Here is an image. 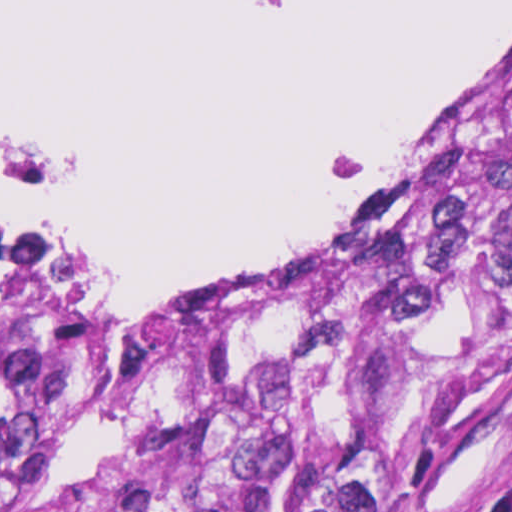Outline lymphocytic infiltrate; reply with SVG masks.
<instances>
[{"mask_svg": "<svg viewBox=\"0 0 512 512\" xmlns=\"http://www.w3.org/2000/svg\"><path fill=\"white\" fill-rule=\"evenodd\" d=\"M463 512H512V484L508 489L507 498L476 505Z\"/></svg>", "mask_w": 512, "mask_h": 512, "instance_id": "lymphocytic-infiltrate-1", "label": "lymphocytic infiltrate"}]
</instances>
